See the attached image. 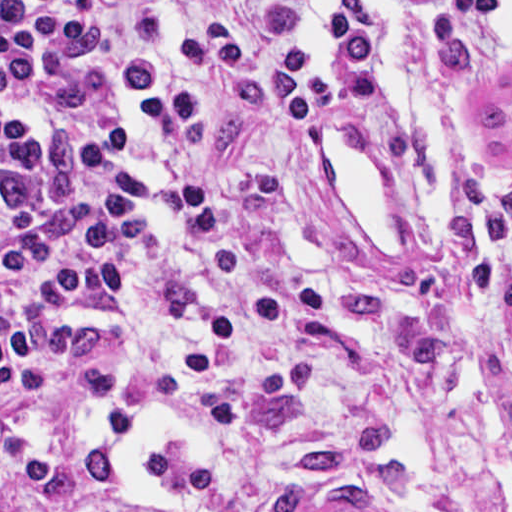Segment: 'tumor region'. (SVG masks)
<instances>
[{
  "mask_svg": "<svg viewBox=\"0 0 512 512\" xmlns=\"http://www.w3.org/2000/svg\"><path fill=\"white\" fill-rule=\"evenodd\" d=\"M80 147L69 131L52 135L40 175L0 173V200L12 206H55L70 192ZM389 444L376 418L348 408L329 425L302 435L278 460L257 512H377L376 491L399 493L411 471L401 451L367 456Z\"/></svg>",
  "mask_w": 512,
  "mask_h": 512,
  "instance_id": "obj_1",
  "label": "tumor region"
}]
</instances>
